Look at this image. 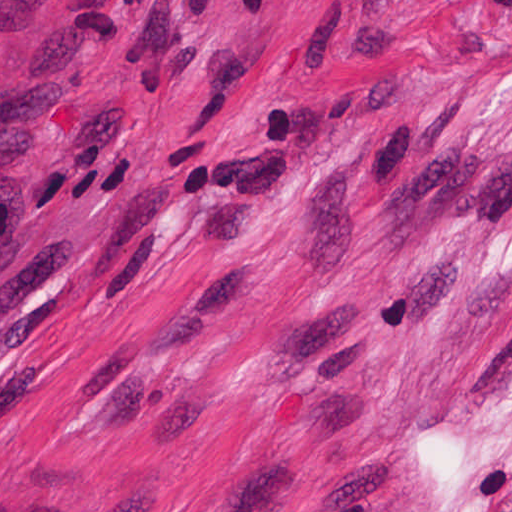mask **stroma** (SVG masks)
<instances>
[{"label":"stroma","instance_id":"obj_1","mask_svg":"<svg viewBox=\"0 0 512 512\" xmlns=\"http://www.w3.org/2000/svg\"><path fill=\"white\" fill-rule=\"evenodd\" d=\"M0 512H512V0H0Z\"/></svg>","mask_w":512,"mask_h":512}]
</instances>
